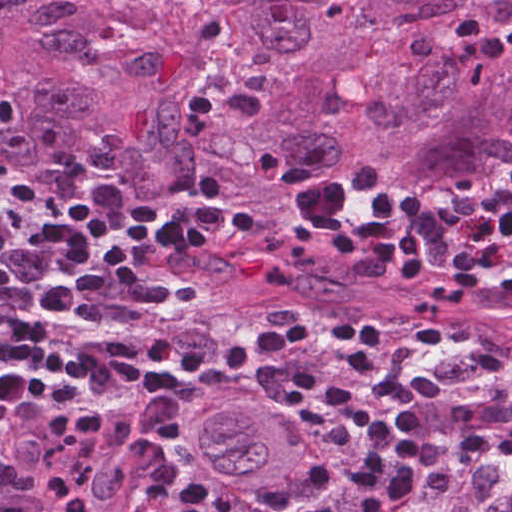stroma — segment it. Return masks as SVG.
Segmentation results:
<instances>
[{
	"label": "stroma",
	"mask_w": 512,
	"mask_h": 512,
	"mask_svg": "<svg viewBox=\"0 0 512 512\" xmlns=\"http://www.w3.org/2000/svg\"><path fill=\"white\" fill-rule=\"evenodd\" d=\"M251 302L284 333L292 317L322 326H339L360 318L297 311L267 301ZM381 326L379 353L396 375H413L417 361L407 345L418 332ZM351 345L348 341L316 340L301 348L484 512H511L512 457H473L459 448L466 433L486 429L512 411V369L503 367V357L502 370L474 397L431 405L422 410L419 425L408 432H398L386 404L371 395L368 374L349 367L346 353ZM481 357L460 341L443 339L432 360L434 377L442 384L466 380L469 368Z\"/></svg>",
	"instance_id": "stroma-1"
}]
</instances>
